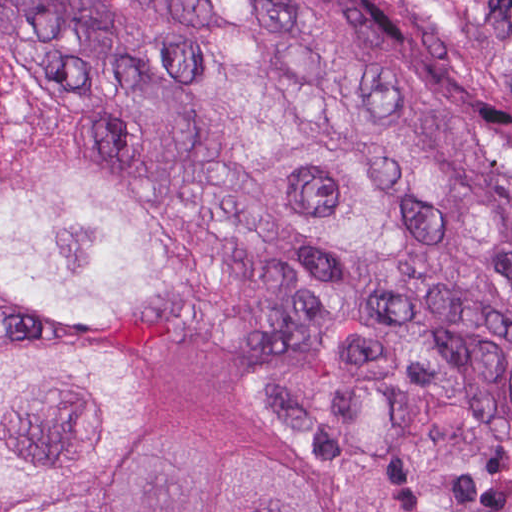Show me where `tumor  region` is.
Wrapping results in <instances>:
<instances>
[{"label": "tumor region", "instance_id": "e687c5a6", "mask_svg": "<svg viewBox=\"0 0 512 512\" xmlns=\"http://www.w3.org/2000/svg\"><path fill=\"white\" fill-rule=\"evenodd\" d=\"M0 310L224 350L343 512H512V0H0ZM0 512H334L0 334Z\"/></svg>", "mask_w": 512, "mask_h": 512}]
</instances>
